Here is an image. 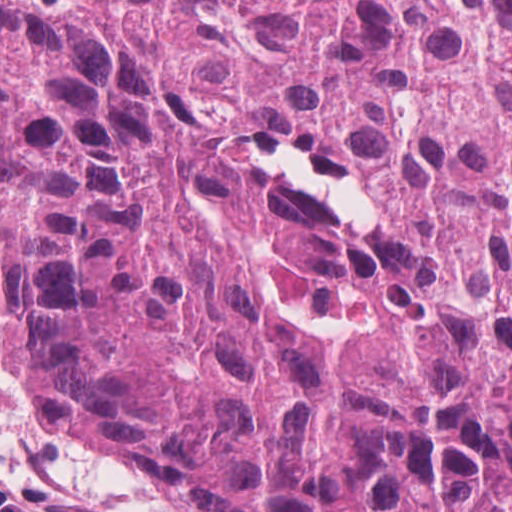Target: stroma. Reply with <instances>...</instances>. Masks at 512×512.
Listing matches in <instances>:
<instances>
[{"mask_svg": "<svg viewBox=\"0 0 512 512\" xmlns=\"http://www.w3.org/2000/svg\"><path fill=\"white\" fill-rule=\"evenodd\" d=\"M67 11L74 0H30ZM0 484L31 512H175L95 446L47 426L8 361L0 326Z\"/></svg>", "mask_w": 512, "mask_h": 512, "instance_id": "35a3bbf8", "label": "stroma"}]
</instances>
